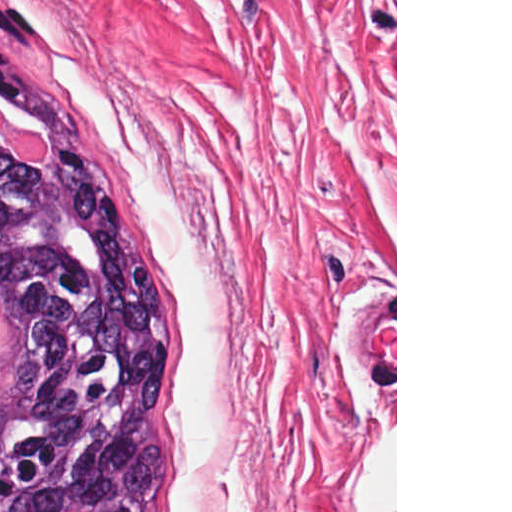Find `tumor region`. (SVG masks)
<instances>
[{
	"instance_id": "e687c5a6",
	"label": "tumor region",
	"mask_w": 512,
	"mask_h": 512,
	"mask_svg": "<svg viewBox=\"0 0 512 512\" xmlns=\"http://www.w3.org/2000/svg\"><path fill=\"white\" fill-rule=\"evenodd\" d=\"M21 90L0 105L49 151L24 162L0 144V512H166L173 308L42 65L33 6L0 0V91Z\"/></svg>"
}]
</instances>
